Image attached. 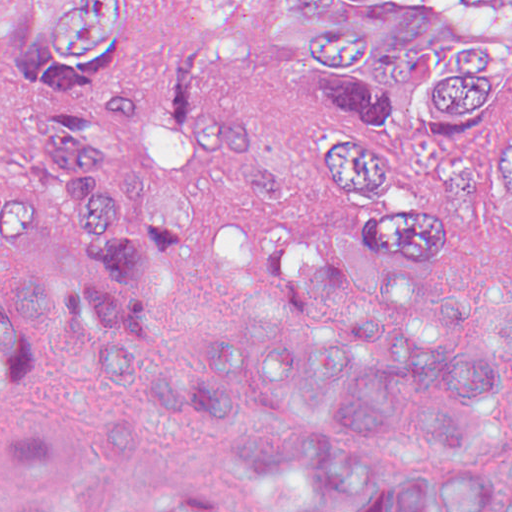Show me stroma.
<instances>
[{
  "label": "stroma",
  "mask_w": 512,
  "mask_h": 512,
  "mask_svg": "<svg viewBox=\"0 0 512 512\" xmlns=\"http://www.w3.org/2000/svg\"><path fill=\"white\" fill-rule=\"evenodd\" d=\"M142 34L135 67L147 82L180 36L201 27L215 38L211 96L245 110L254 145L283 184L322 168V140L386 136L397 120L441 145H482L503 122L512 94V0L482 9L468 0H361L400 42L440 47L466 37L499 48L507 81L496 88L486 121L471 130L443 129L434 117L440 72L382 83L363 68L357 81H307L304 49L313 20L283 9V0H133ZM38 123L21 56H0V194L17 190L24 153ZM263 193L241 173L207 162L197 201L241 209Z\"/></svg>",
  "instance_id": "obj_1"
}]
</instances>
